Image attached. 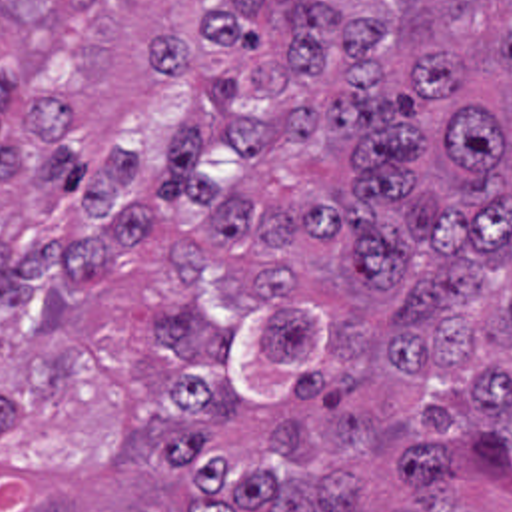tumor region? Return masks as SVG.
Masks as SVG:
<instances>
[{
	"label": "tumor region",
	"mask_w": 512,
	"mask_h": 512,
	"mask_svg": "<svg viewBox=\"0 0 512 512\" xmlns=\"http://www.w3.org/2000/svg\"><path fill=\"white\" fill-rule=\"evenodd\" d=\"M0 512H512V0H0Z\"/></svg>",
	"instance_id": "e687c5a6"
}]
</instances>
